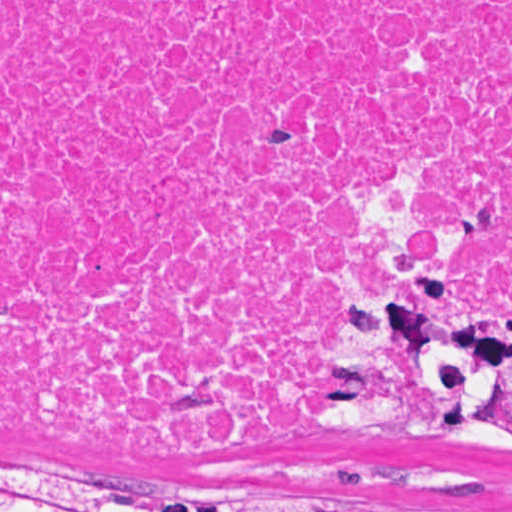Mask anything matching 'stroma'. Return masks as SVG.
Returning a JSON list of instances; mask_svg holds the SVG:
<instances>
[{
	"label": "stroma",
	"instance_id": "obj_1",
	"mask_svg": "<svg viewBox=\"0 0 512 512\" xmlns=\"http://www.w3.org/2000/svg\"><path fill=\"white\" fill-rule=\"evenodd\" d=\"M408 255L437 302L480 318L512 322V304L469 291L462 262L424 243L380 232L347 250L335 283L314 314L308 372L315 390L314 420L288 455L265 461H189L55 445L0 426V467L83 473L162 503H239L307 506L336 512L337 492L367 495V512L512 510V455L447 441H367L329 425L323 398L331 384L320 369L318 341L347 283L371 258Z\"/></svg>",
	"mask_w": 512,
	"mask_h": 512
}]
</instances>
